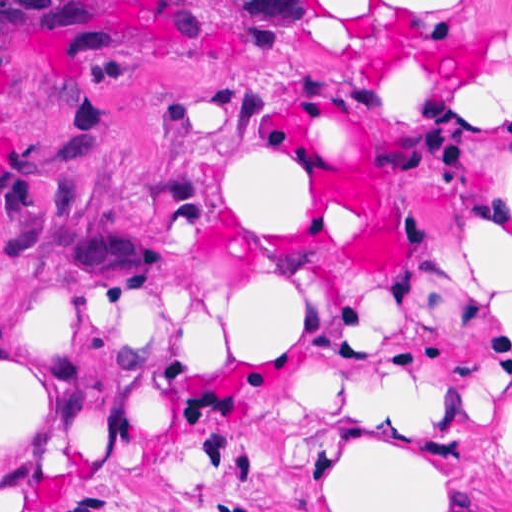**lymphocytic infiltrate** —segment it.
<instances>
[{
    "label": "lymphocytic infiltrate",
    "instance_id": "obj_1",
    "mask_svg": "<svg viewBox=\"0 0 512 512\" xmlns=\"http://www.w3.org/2000/svg\"><path fill=\"white\" fill-rule=\"evenodd\" d=\"M24 37L55 56H104L119 42V26L93 1H0V92Z\"/></svg>",
    "mask_w": 512,
    "mask_h": 512
}]
</instances>
